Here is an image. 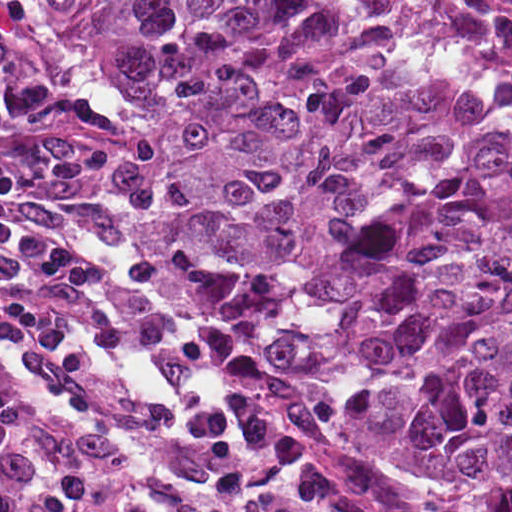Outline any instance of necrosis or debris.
Here are the masks:
<instances>
[{"label":"necrosis or debris","instance_id":"obj_1","mask_svg":"<svg viewBox=\"0 0 512 512\" xmlns=\"http://www.w3.org/2000/svg\"><path fill=\"white\" fill-rule=\"evenodd\" d=\"M408 49L460 79L512 97V1H365Z\"/></svg>","mask_w":512,"mask_h":512}]
</instances>
